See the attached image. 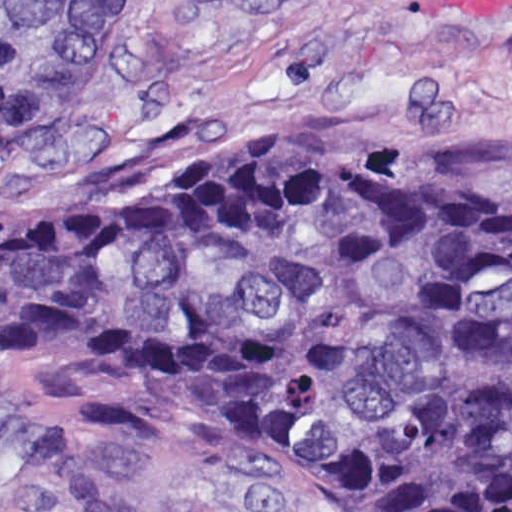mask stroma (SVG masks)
<instances>
[{
    "label": "stroma",
    "mask_w": 512,
    "mask_h": 512,
    "mask_svg": "<svg viewBox=\"0 0 512 512\" xmlns=\"http://www.w3.org/2000/svg\"><path fill=\"white\" fill-rule=\"evenodd\" d=\"M271 132H377L512 166V0H135L88 98L0 161V216L136 183ZM11 391L0 512H412L247 425L53 358Z\"/></svg>",
    "instance_id": "obj_1"
}]
</instances>
